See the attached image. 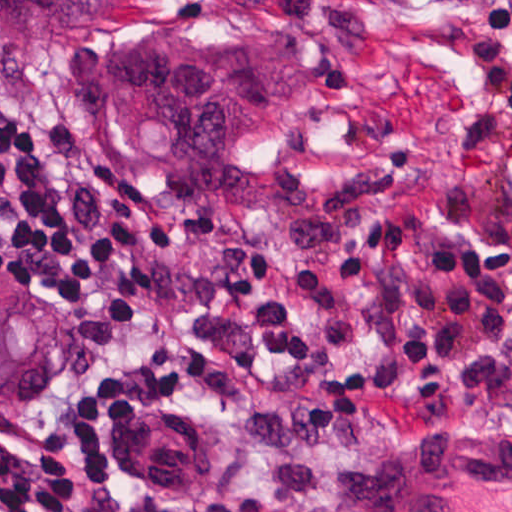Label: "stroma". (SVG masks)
Masks as SVG:
<instances>
[{"label": "stroma", "instance_id": "stroma-1", "mask_svg": "<svg viewBox=\"0 0 512 512\" xmlns=\"http://www.w3.org/2000/svg\"><path fill=\"white\" fill-rule=\"evenodd\" d=\"M236 18L310 59L306 127L271 161L316 179V209L235 201H153L114 168L80 93L90 39L0 52V95L38 119L40 157L84 238L137 220L157 293L118 339L93 346L62 291L27 288L66 325V370L48 396L0 410V439L43 450L58 419L162 342L177 338L237 369V388L183 386L177 412L211 430L208 473L185 490L109 481L93 512H362L390 462L430 444H473L512 431V400L418 412L307 417L310 379L256 346L251 319L186 296L195 269L228 247L269 249L291 269L326 264L389 205H435L446 226L512 240V0H104V24ZM142 306L131 308L140 309Z\"/></svg>", "mask_w": 512, "mask_h": 512}]
</instances>
